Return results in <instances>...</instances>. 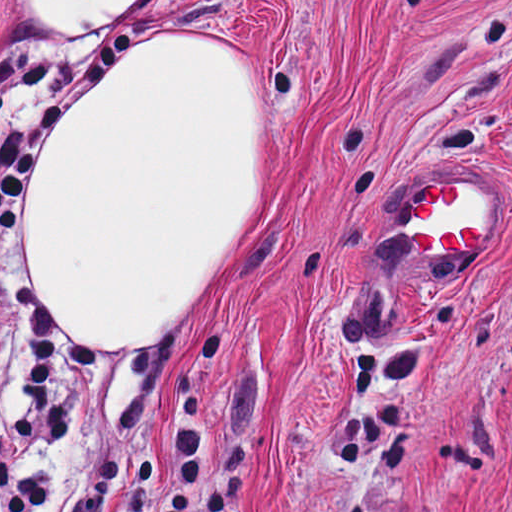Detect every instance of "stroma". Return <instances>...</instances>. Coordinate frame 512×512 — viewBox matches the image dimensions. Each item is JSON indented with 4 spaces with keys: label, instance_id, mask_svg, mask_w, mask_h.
<instances>
[{
    "label": "stroma",
    "instance_id": "35a3bbf8",
    "mask_svg": "<svg viewBox=\"0 0 512 512\" xmlns=\"http://www.w3.org/2000/svg\"><path fill=\"white\" fill-rule=\"evenodd\" d=\"M18 1H150L238 46L263 108V204L222 250L160 355H100L58 330L73 436L40 512L119 463L101 512H169L181 365L205 385L206 467L189 512H512V0H0V58L39 55L44 102L109 35L21 19ZM100 67L80 92L100 84ZM492 180L471 260H421L411 200ZM0 233V433L30 408Z\"/></svg>",
    "mask_w": 512,
    "mask_h": 512
}]
</instances>
